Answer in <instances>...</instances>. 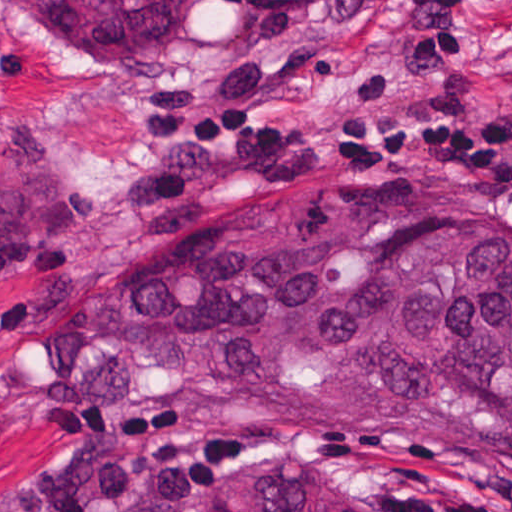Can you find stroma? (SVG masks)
Wrapping results in <instances>:
<instances>
[{
	"label": "stroma",
	"instance_id": "1",
	"mask_svg": "<svg viewBox=\"0 0 512 512\" xmlns=\"http://www.w3.org/2000/svg\"><path fill=\"white\" fill-rule=\"evenodd\" d=\"M472 46L439 69L408 67L406 17L377 0L306 16L187 8L150 51L77 54L21 28L0 5V187L41 182L64 199V237L36 270L0 288V512H40L38 494L67 462L51 429L132 426L159 413L229 423L240 443L218 484L269 468L305 474L367 512L400 491L512 493V465L464 452H358L316 444L226 411L190 384L125 416L52 407L24 360L87 283L133 266L171 236L264 197L333 187H424L473 199L512 193L449 166L386 157H286L232 191L151 220H123L113 192L154 162L174 103L211 96L274 124H332L364 104H512V0H459Z\"/></svg>",
	"mask_w": 512,
	"mask_h": 512
}]
</instances>
